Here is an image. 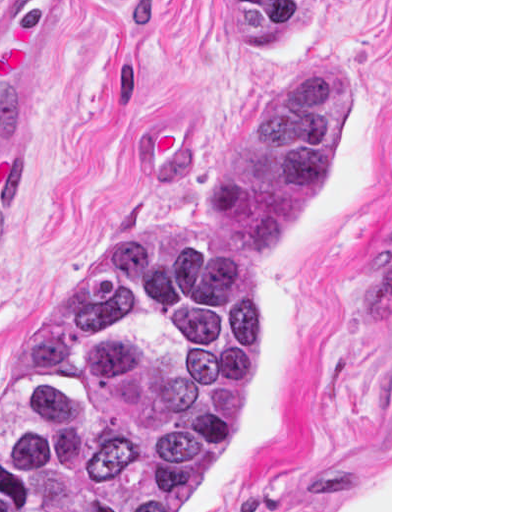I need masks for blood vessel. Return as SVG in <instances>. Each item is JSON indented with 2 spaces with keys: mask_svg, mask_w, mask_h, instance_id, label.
<instances>
[{
  "mask_svg": "<svg viewBox=\"0 0 512 512\" xmlns=\"http://www.w3.org/2000/svg\"><path fill=\"white\" fill-rule=\"evenodd\" d=\"M71 0H0V142L23 117L49 67Z\"/></svg>",
  "mask_w": 512,
  "mask_h": 512,
  "instance_id": "8fb6f2fc",
  "label": "blood vessel"
}]
</instances>
